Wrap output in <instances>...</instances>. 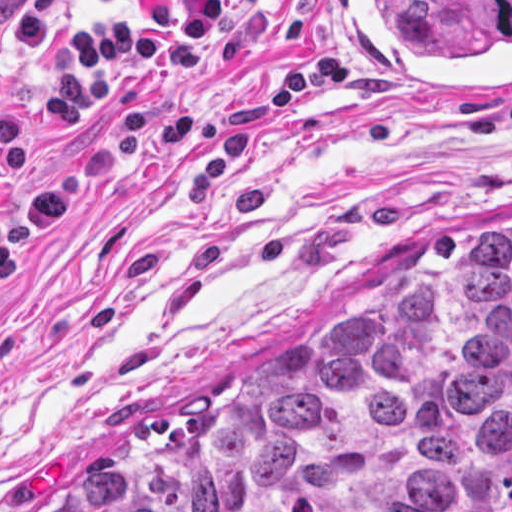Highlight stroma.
Returning <instances> with one entry per match:
<instances>
[{
  "label": "stroma",
  "instance_id": "obj_1",
  "mask_svg": "<svg viewBox=\"0 0 512 512\" xmlns=\"http://www.w3.org/2000/svg\"><path fill=\"white\" fill-rule=\"evenodd\" d=\"M123 0H69L67 24ZM238 54L173 72L191 130L134 151L0 286V512H63L104 472L354 312L512 235V97L351 82L333 0H256ZM51 54L3 34L0 101L33 128L18 194L66 175L111 107L43 108Z\"/></svg>",
  "mask_w": 512,
  "mask_h": 512
}]
</instances>
